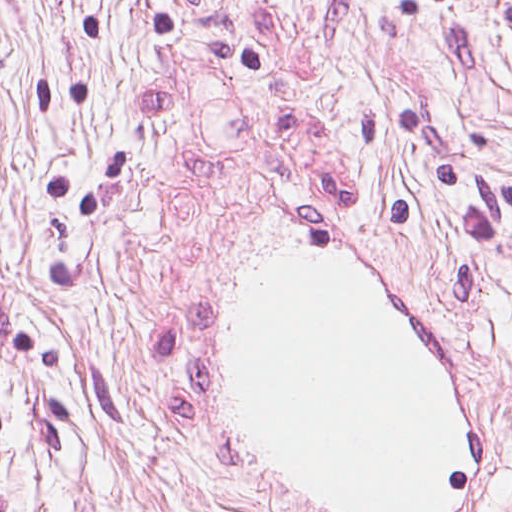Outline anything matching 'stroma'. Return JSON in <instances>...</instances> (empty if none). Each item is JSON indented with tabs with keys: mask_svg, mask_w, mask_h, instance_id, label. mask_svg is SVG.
Listing matches in <instances>:
<instances>
[{
	"mask_svg": "<svg viewBox=\"0 0 512 512\" xmlns=\"http://www.w3.org/2000/svg\"><path fill=\"white\" fill-rule=\"evenodd\" d=\"M242 268L0 214V512H350L260 466L214 404ZM388 298L458 402L447 512H512V323Z\"/></svg>",
	"mask_w": 512,
	"mask_h": 512,
	"instance_id": "1",
	"label": "stroma"
}]
</instances>
